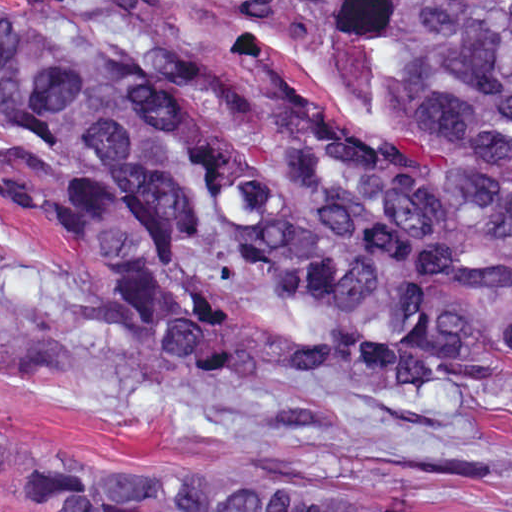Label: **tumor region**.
Wrapping results in <instances>:
<instances>
[{
	"instance_id": "tumor-region-1",
	"label": "tumor region",
	"mask_w": 512,
	"mask_h": 512,
	"mask_svg": "<svg viewBox=\"0 0 512 512\" xmlns=\"http://www.w3.org/2000/svg\"><path fill=\"white\" fill-rule=\"evenodd\" d=\"M145 2L0 1V111L98 280L0 267V318L61 320L247 404L462 413L488 386L483 345L512 359V1H214L273 29L324 21L443 160L357 145L323 112L202 110ZM10 463L23 512H461L430 484L306 457L39 454L0 425Z\"/></svg>"
}]
</instances>
